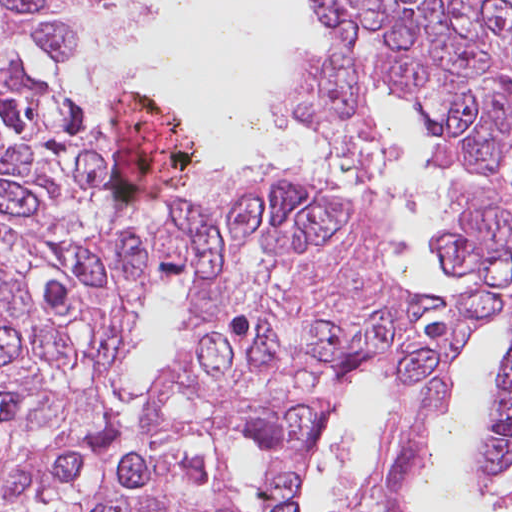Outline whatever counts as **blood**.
Masks as SVG:
<instances>
[{"mask_svg": "<svg viewBox=\"0 0 512 512\" xmlns=\"http://www.w3.org/2000/svg\"><path fill=\"white\" fill-rule=\"evenodd\" d=\"M120 132L113 139L116 200L140 201L175 188L192 170L194 151L188 133L157 99L136 93L109 118Z\"/></svg>", "mask_w": 512, "mask_h": 512, "instance_id": "1a1defca", "label": "blood"}]
</instances>
